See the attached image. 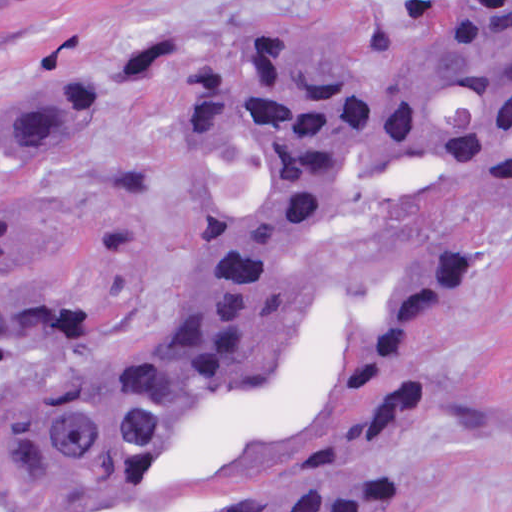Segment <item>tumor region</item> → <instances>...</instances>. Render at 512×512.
I'll use <instances>...</instances> for the list:
<instances>
[{
  "label": "tumor region",
  "instance_id": "tumor-region-1",
  "mask_svg": "<svg viewBox=\"0 0 512 512\" xmlns=\"http://www.w3.org/2000/svg\"><path fill=\"white\" fill-rule=\"evenodd\" d=\"M97 109L73 74L11 90L1 164L76 153ZM177 122L187 287L136 348L21 291L75 231L0 194V512H402L390 458L460 403L428 353L478 250L440 235L376 282H302L288 259L340 211L512 188V0H447L430 42L376 74L255 33L182 76Z\"/></svg>",
  "mask_w": 512,
  "mask_h": 512
}]
</instances>
